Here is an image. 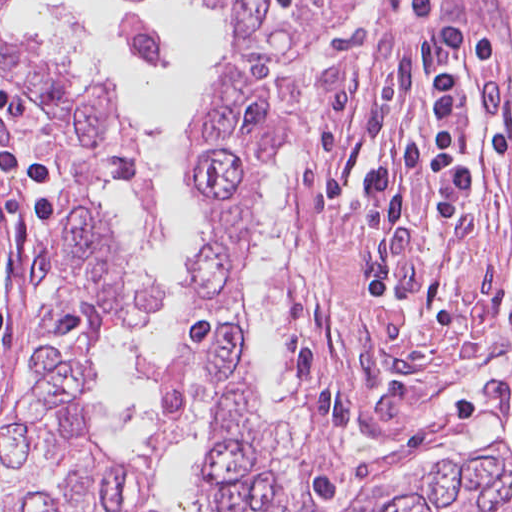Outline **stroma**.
Returning <instances> with one entry per match:
<instances>
[{
  "label": "stroma",
  "instance_id": "1",
  "mask_svg": "<svg viewBox=\"0 0 512 512\" xmlns=\"http://www.w3.org/2000/svg\"><path fill=\"white\" fill-rule=\"evenodd\" d=\"M293 59L309 70L282 213L291 249L311 261L313 288L284 304L286 361L302 400L301 432L283 452L302 496L342 504L391 495L424 468L489 445L512 459V0H329ZM451 68L462 91L464 200L434 221L417 178L390 222H371V175L404 142L434 134L429 85ZM0 92L21 109L0 112V294L11 318L0 335L1 419L44 359L70 253L49 107L2 73ZM12 150L43 164L54 239L30 187L1 161ZM282 157L257 205L245 267ZM167 216L165 203L164 230ZM202 220L183 267L207 240ZM381 269L393 271L397 312L369 298L362 277Z\"/></svg>",
  "mask_w": 512,
  "mask_h": 512
}]
</instances>
